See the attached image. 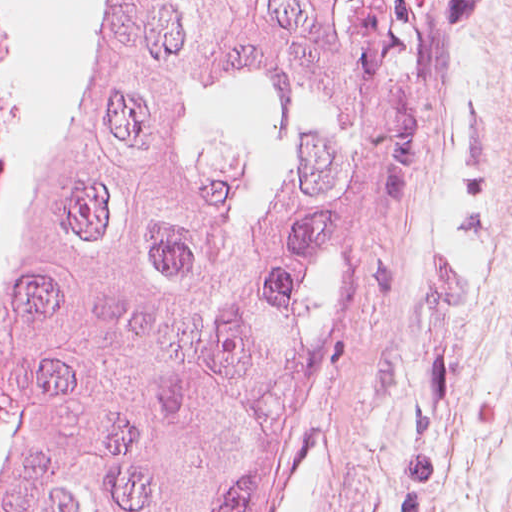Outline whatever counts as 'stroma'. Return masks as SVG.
I'll list each match as a JSON object with an SVG mask.
<instances>
[{
	"label": "stroma",
	"instance_id": "1",
	"mask_svg": "<svg viewBox=\"0 0 512 512\" xmlns=\"http://www.w3.org/2000/svg\"><path fill=\"white\" fill-rule=\"evenodd\" d=\"M422 2L423 0H376V28L385 50L405 57H411ZM354 324L334 393L312 482L287 512L315 511Z\"/></svg>",
	"mask_w": 512,
	"mask_h": 512
}]
</instances>
